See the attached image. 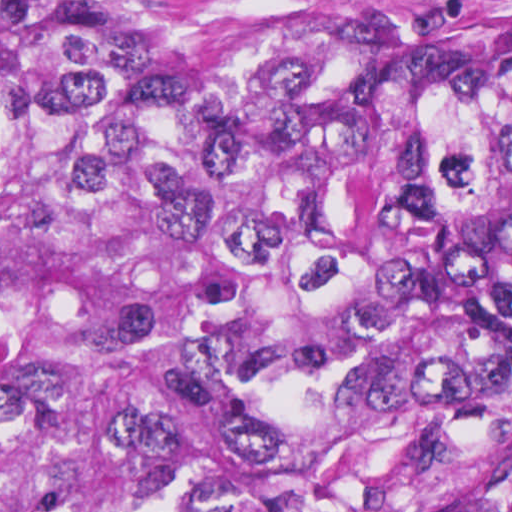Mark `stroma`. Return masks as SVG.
Wrapping results in <instances>:
<instances>
[{"instance_id": "35a3bbf8", "label": "stroma", "mask_w": 512, "mask_h": 512, "mask_svg": "<svg viewBox=\"0 0 512 512\" xmlns=\"http://www.w3.org/2000/svg\"><path fill=\"white\" fill-rule=\"evenodd\" d=\"M149 35L155 83L212 93L217 69L308 29L422 23L512 35V0H134Z\"/></svg>"}]
</instances>
